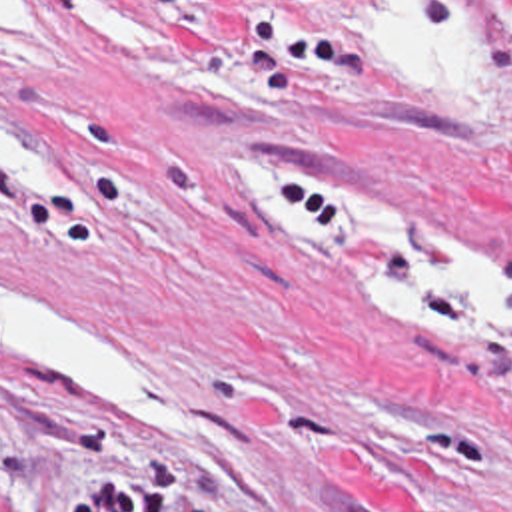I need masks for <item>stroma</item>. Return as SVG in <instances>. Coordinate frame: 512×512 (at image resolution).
I'll return each mask as SVG.
<instances>
[{"label":"stroma","mask_w":512,"mask_h":512,"mask_svg":"<svg viewBox=\"0 0 512 512\" xmlns=\"http://www.w3.org/2000/svg\"><path fill=\"white\" fill-rule=\"evenodd\" d=\"M228 172L326 178L512 266V62L431 84L346 0H10L0 264L218 462L0 370V512H512L511 358L282 258Z\"/></svg>","instance_id":"stroma-1"}]
</instances>
